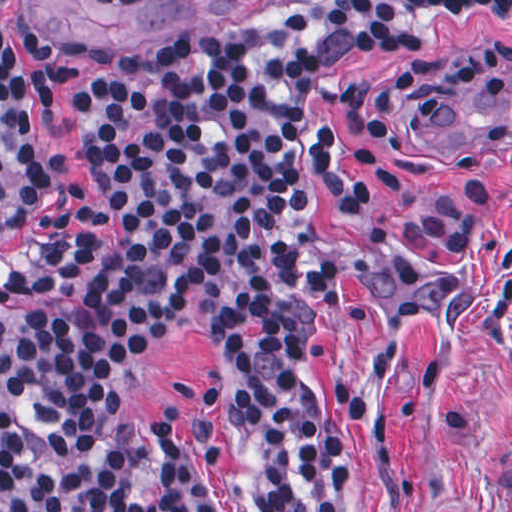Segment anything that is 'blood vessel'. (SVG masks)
I'll list each match as a JSON object with an SVG mask.
<instances>
[{"label": "blood vessel", "mask_w": 512, "mask_h": 512, "mask_svg": "<svg viewBox=\"0 0 512 512\" xmlns=\"http://www.w3.org/2000/svg\"><path fill=\"white\" fill-rule=\"evenodd\" d=\"M434 102L439 150L512 153V69L465 74Z\"/></svg>", "instance_id": "1"}]
</instances>
